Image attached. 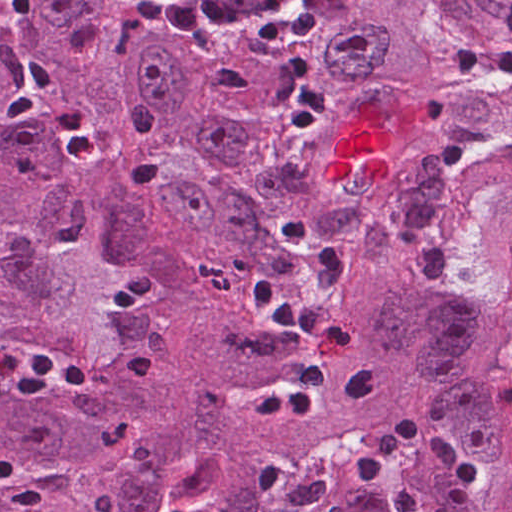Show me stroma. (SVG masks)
I'll return each instance as SVG.
<instances>
[{
    "instance_id": "obj_1",
    "label": "stroma",
    "mask_w": 512,
    "mask_h": 512,
    "mask_svg": "<svg viewBox=\"0 0 512 512\" xmlns=\"http://www.w3.org/2000/svg\"><path fill=\"white\" fill-rule=\"evenodd\" d=\"M115 1L122 6L120 0H115ZM346 1L347 0H327L324 26L313 31V32L306 33V34L296 36V37L274 35V36H262V37H254V38L234 39V40H231L229 42H226V43H223L220 45H233V46H244V47L257 48V47L268 46V45L285 44V43H288V42H291V41H294V40H297L300 38L314 39L318 35V33L326 26V24L333 18V16L339 11V9L345 4ZM185 51H201V50H185ZM311 449H312V447L307 451V453L303 457H305Z\"/></svg>"
}]
</instances>
